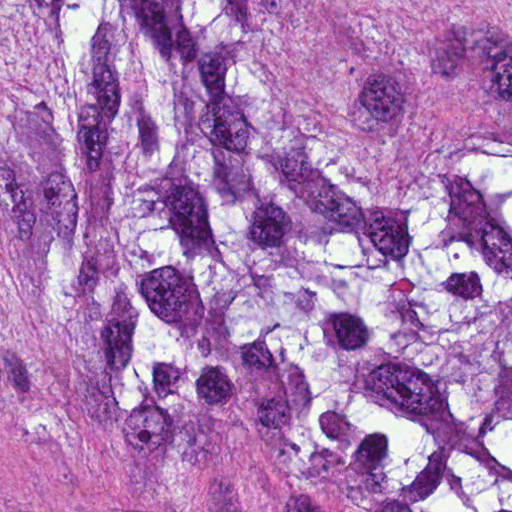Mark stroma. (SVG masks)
I'll return each mask as SVG.
<instances>
[{
	"label": "stroma",
	"instance_id": "35a3bbf8",
	"mask_svg": "<svg viewBox=\"0 0 512 512\" xmlns=\"http://www.w3.org/2000/svg\"><path fill=\"white\" fill-rule=\"evenodd\" d=\"M0 512L378 511L228 430L117 424L61 382L6 377L0 380Z\"/></svg>",
	"mask_w": 512,
	"mask_h": 512
}]
</instances>
